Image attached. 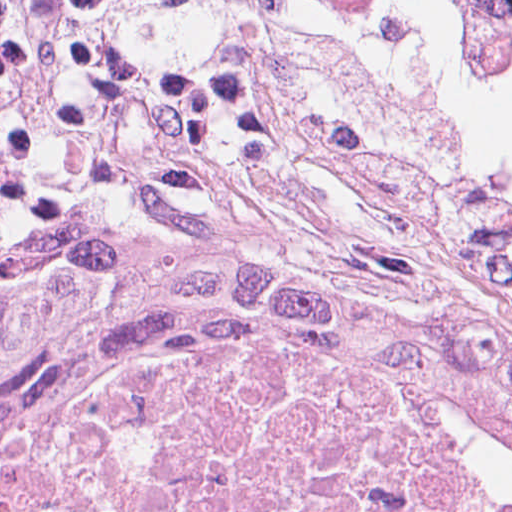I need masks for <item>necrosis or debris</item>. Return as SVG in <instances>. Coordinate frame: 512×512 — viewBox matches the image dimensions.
Returning <instances> with one entry per match:
<instances>
[{
  "label": "necrosis or debris",
  "mask_w": 512,
  "mask_h": 512,
  "mask_svg": "<svg viewBox=\"0 0 512 512\" xmlns=\"http://www.w3.org/2000/svg\"><path fill=\"white\" fill-rule=\"evenodd\" d=\"M0 512H512V411L67 338L0 372Z\"/></svg>",
  "instance_id": "4bbe7bcc"
}]
</instances>
